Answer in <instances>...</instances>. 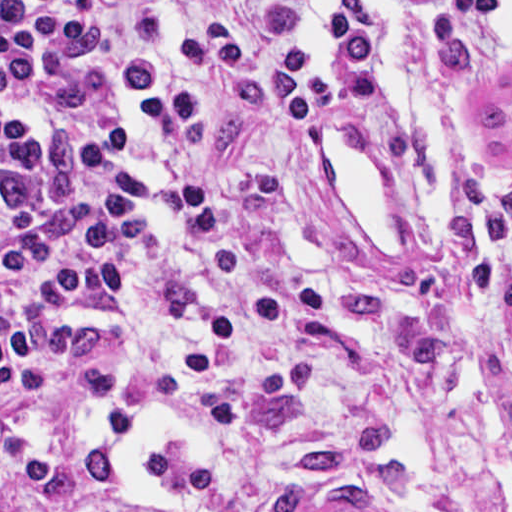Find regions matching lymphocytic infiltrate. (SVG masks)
Masks as SVG:
<instances>
[{
  "label": "lymphocytic infiltrate",
  "mask_w": 512,
  "mask_h": 512,
  "mask_svg": "<svg viewBox=\"0 0 512 512\" xmlns=\"http://www.w3.org/2000/svg\"><path fill=\"white\" fill-rule=\"evenodd\" d=\"M377 0H0V512H224L270 356L323 313L248 238L301 131L383 84Z\"/></svg>",
  "instance_id": "obj_1"
}]
</instances>
